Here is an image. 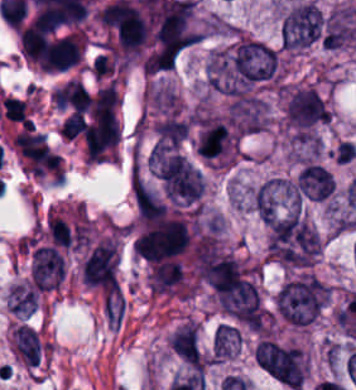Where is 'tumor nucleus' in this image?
Returning <instances> with one entry per match:
<instances>
[{
  "label": "tumor nucleus",
  "instance_id": "obj_1",
  "mask_svg": "<svg viewBox=\"0 0 356 390\" xmlns=\"http://www.w3.org/2000/svg\"><path fill=\"white\" fill-rule=\"evenodd\" d=\"M319 248L314 227L299 216L266 220V251L275 264L290 270L305 269L316 259Z\"/></svg>",
  "mask_w": 356,
  "mask_h": 390
},
{
  "label": "tumor nucleus",
  "instance_id": "obj_2",
  "mask_svg": "<svg viewBox=\"0 0 356 390\" xmlns=\"http://www.w3.org/2000/svg\"><path fill=\"white\" fill-rule=\"evenodd\" d=\"M322 23L321 10L308 1L291 4L280 21L281 49L286 52H295L319 42Z\"/></svg>",
  "mask_w": 356,
  "mask_h": 390
},
{
  "label": "tumor nucleus",
  "instance_id": "obj_3",
  "mask_svg": "<svg viewBox=\"0 0 356 390\" xmlns=\"http://www.w3.org/2000/svg\"><path fill=\"white\" fill-rule=\"evenodd\" d=\"M254 359L265 374L290 389L295 390L303 379L300 352L294 346L261 337Z\"/></svg>",
  "mask_w": 356,
  "mask_h": 390
},
{
  "label": "tumor nucleus",
  "instance_id": "obj_4",
  "mask_svg": "<svg viewBox=\"0 0 356 390\" xmlns=\"http://www.w3.org/2000/svg\"><path fill=\"white\" fill-rule=\"evenodd\" d=\"M296 196L308 201H325L332 197L334 179L327 167L316 162H303L293 182Z\"/></svg>",
  "mask_w": 356,
  "mask_h": 390
},
{
  "label": "tumor nucleus",
  "instance_id": "obj_5",
  "mask_svg": "<svg viewBox=\"0 0 356 390\" xmlns=\"http://www.w3.org/2000/svg\"><path fill=\"white\" fill-rule=\"evenodd\" d=\"M169 349L186 361L198 360L199 345L194 325L188 320L174 329L167 337Z\"/></svg>",
  "mask_w": 356,
  "mask_h": 390
},
{
  "label": "tumor nucleus",
  "instance_id": "obj_6",
  "mask_svg": "<svg viewBox=\"0 0 356 390\" xmlns=\"http://www.w3.org/2000/svg\"><path fill=\"white\" fill-rule=\"evenodd\" d=\"M11 347L23 363L34 365L40 349L36 332L27 325L16 324L10 330Z\"/></svg>",
  "mask_w": 356,
  "mask_h": 390
},
{
  "label": "tumor nucleus",
  "instance_id": "obj_7",
  "mask_svg": "<svg viewBox=\"0 0 356 390\" xmlns=\"http://www.w3.org/2000/svg\"><path fill=\"white\" fill-rule=\"evenodd\" d=\"M241 332L237 325L219 322L212 331L211 353L216 357L232 355L240 345Z\"/></svg>",
  "mask_w": 356,
  "mask_h": 390
},
{
  "label": "tumor nucleus",
  "instance_id": "obj_8",
  "mask_svg": "<svg viewBox=\"0 0 356 390\" xmlns=\"http://www.w3.org/2000/svg\"><path fill=\"white\" fill-rule=\"evenodd\" d=\"M7 309L30 314L36 307L34 289L30 285L11 284L6 291Z\"/></svg>",
  "mask_w": 356,
  "mask_h": 390
}]
</instances>
